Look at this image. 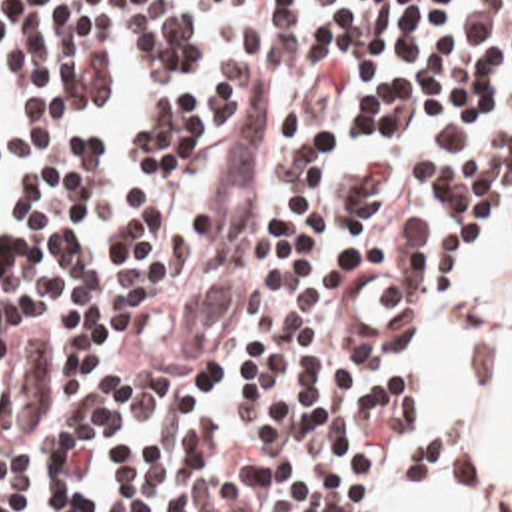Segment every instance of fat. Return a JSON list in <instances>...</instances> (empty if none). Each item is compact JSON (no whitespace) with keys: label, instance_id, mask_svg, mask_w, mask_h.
Listing matches in <instances>:
<instances>
[{"label":"fat","instance_id":"53f6f03d","mask_svg":"<svg viewBox=\"0 0 512 512\" xmlns=\"http://www.w3.org/2000/svg\"><path fill=\"white\" fill-rule=\"evenodd\" d=\"M502 512H512V392L502 414Z\"/></svg>","mask_w":512,"mask_h":512}]
</instances>
